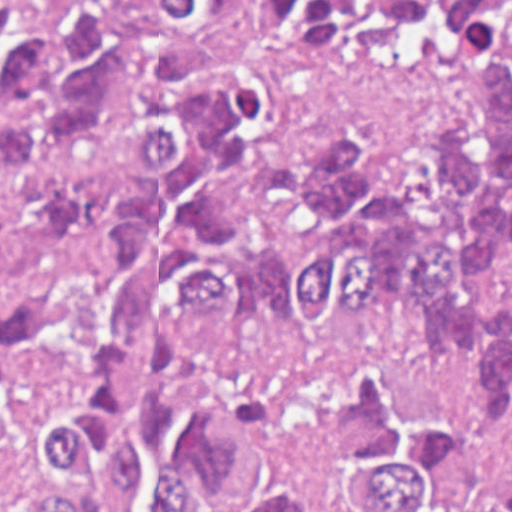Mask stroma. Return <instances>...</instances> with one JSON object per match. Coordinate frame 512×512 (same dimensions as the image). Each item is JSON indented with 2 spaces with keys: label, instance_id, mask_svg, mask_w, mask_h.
I'll return each instance as SVG.
<instances>
[{
  "label": "stroma",
  "instance_id": "1",
  "mask_svg": "<svg viewBox=\"0 0 512 512\" xmlns=\"http://www.w3.org/2000/svg\"><path fill=\"white\" fill-rule=\"evenodd\" d=\"M215 61L253 84L265 142L308 146L327 130L371 138L377 159L415 158L467 93L473 68L461 46L430 22H410L381 48L342 61L299 57L265 35L252 0H233ZM0 512H37L24 448L0 443Z\"/></svg>",
  "mask_w": 512,
  "mask_h": 512
}]
</instances>
